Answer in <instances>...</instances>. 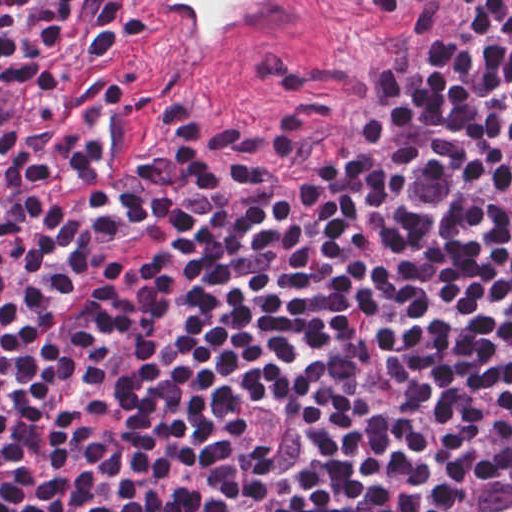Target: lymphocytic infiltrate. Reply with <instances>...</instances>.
Returning a JSON list of instances; mask_svg holds the SVG:
<instances>
[{
	"mask_svg": "<svg viewBox=\"0 0 512 512\" xmlns=\"http://www.w3.org/2000/svg\"><path fill=\"white\" fill-rule=\"evenodd\" d=\"M343 21L164 158L105 0H0V512H512V0Z\"/></svg>",
	"mask_w": 512,
	"mask_h": 512,
	"instance_id": "1",
	"label": "lymphocytic infiltrate"
}]
</instances>
